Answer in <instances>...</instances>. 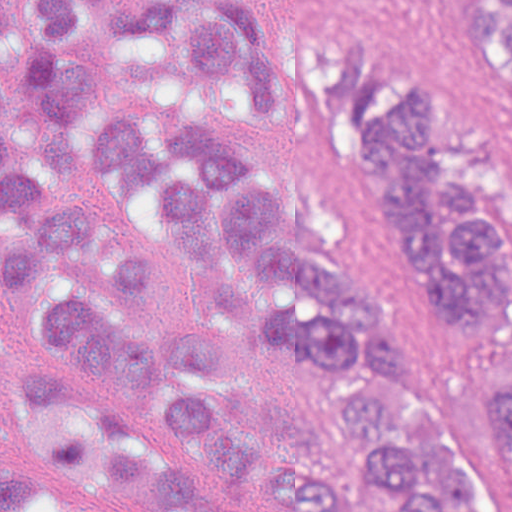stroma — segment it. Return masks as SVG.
I'll return each mask as SVG.
<instances>
[{
  "label": "stroma",
  "instance_id": "obj_1",
  "mask_svg": "<svg viewBox=\"0 0 512 512\" xmlns=\"http://www.w3.org/2000/svg\"><path fill=\"white\" fill-rule=\"evenodd\" d=\"M266 35L313 21L378 44L454 90L465 110L483 173L512 223V78L460 19L453 0H250ZM91 91L68 125L79 163L76 186L53 189L96 230L148 261L154 296L137 299L157 355V334L217 320L206 290L175 233L158 189L94 182L86 163L90 114L127 102L160 122H221L246 147L271 189L283 196V237L365 294L389 324L400 364L440 419L482 512H509L471 434L468 347L407 279L373 201L367 161L334 134L293 125L271 109L257 115L217 87L197 83L171 46L150 33H83ZM4 226L0 207V232ZM47 276L10 292L0 282V336L14 351L96 364L47 339ZM158 372L159 366H158ZM229 413L252 437L250 509L282 512L259 477L263 455L303 451L330 479L350 483L377 456L341 429L337 406L355 377L296 346L259 339L226 376ZM348 512H397L392 483L368 476L350 484Z\"/></svg>",
  "mask_w": 512,
  "mask_h": 512
}]
</instances>
